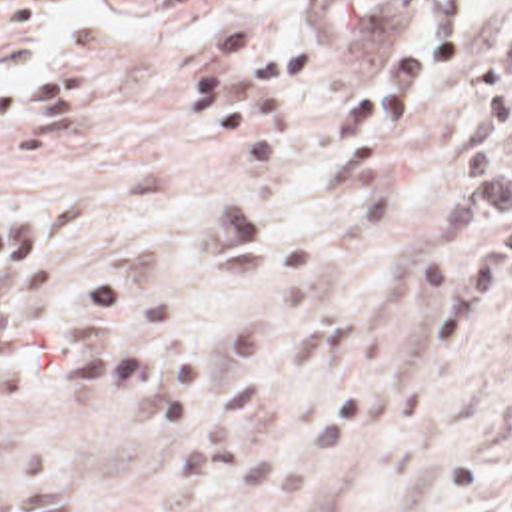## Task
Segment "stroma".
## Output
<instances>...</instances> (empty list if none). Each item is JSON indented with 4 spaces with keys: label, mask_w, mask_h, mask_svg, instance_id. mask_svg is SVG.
<instances>
[{
    "label": "stroma",
    "mask_w": 512,
    "mask_h": 512,
    "mask_svg": "<svg viewBox=\"0 0 512 512\" xmlns=\"http://www.w3.org/2000/svg\"><path fill=\"white\" fill-rule=\"evenodd\" d=\"M356 45L378 53L457 27L467 63L390 191L346 173L344 103L362 51L290 111L284 155L254 181L240 141L164 127L168 81L198 33L248 13L282 31L300 5L264 0H0V211L38 207L64 229V293L112 265L174 309L182 229L216 207L274 229L264 277L198 321L208 345L274 327L280 392L244 436L316 472L260 498H180L178 428L36 370L0 404V512H512V273L485 329L426 341L438 293L430 251L475 243L432 231L481 103L473 61L512 25V0H364ZM186 422V414L182 418Z\"/></svg>",
    "instance_id": "35a3bbf8"
}]
</instances>
